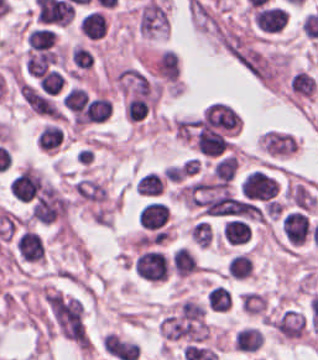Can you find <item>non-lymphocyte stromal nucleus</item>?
<instances>
[{"label":"non-lymphocyte stromal nucleus","mask_w":318,"mask_h":360,"mask_svg":"<svg viewBox=\"0 0 318 360\" xmlns=\"http://www.w3.org/2000/svg\"><path fill=\"white\" fill-rule=\"evenodd\" d=\"M44 302L54 328L71 340H84L83 303L57 292L44 295Z\"/></svg>","instance_id":"obj_1"},{"label":"non-lymphocyte stromal nucleus","mask_w":318,"mask_h":360,"mask_svg":"<svg viewBox=\"0 0 318 360\" xmlns=\"http://www.w3.org/2000/svg\"><path fill=\"white\" fill-rule=\"evenodd\" d=\"M240 121V117L232 106L212 102L206 109L201 124L214 129L237 130Z\"/></svg>","instance_id":"obj_2"}]
</instances>
